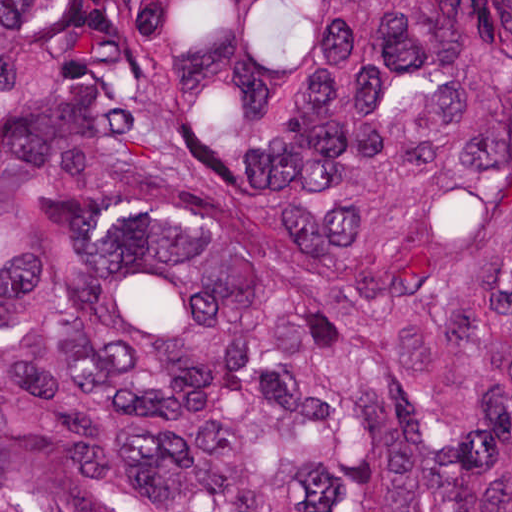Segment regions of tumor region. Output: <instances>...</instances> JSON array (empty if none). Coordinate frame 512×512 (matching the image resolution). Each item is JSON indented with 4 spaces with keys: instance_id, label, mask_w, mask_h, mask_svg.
<instances>
[{
    "instance_id": "1",
    "label": "tumor region",
    "mask_w": 512,
    "mask_h": 512,
    "mask_svg": "<svg viewBox=\"0 0 512 512\" xmlns=\"http://www.w3.org/2000/svg\"><path fill=\"white\" fill-rule=\"evenodd\" d=\"M0 512H512V0H0Z\"/></svg>"
}]
</instances>
